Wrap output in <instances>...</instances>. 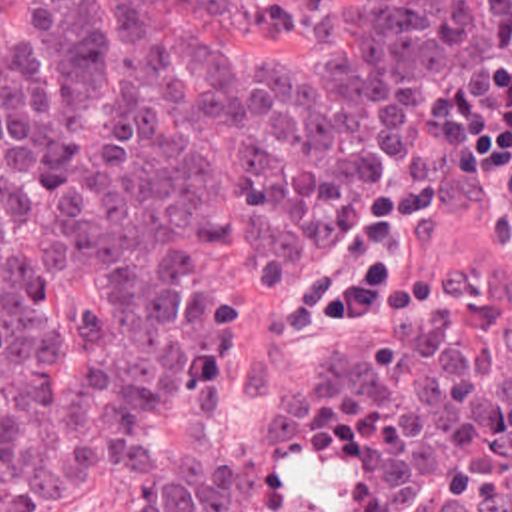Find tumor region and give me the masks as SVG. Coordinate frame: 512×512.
Returning a JSON list of instances; mask_svg holds the SVG:
<instances>
[{
	"instance_id": "1",
	"label": "tumor region",
	"mask_w": 512,
	"mask_h": 512,
	"mask_svg": "<svg viewBox=\"0 0 512 512\" xmlns=\"http://www.w3.org/2000/svg\"><path fill=\"white\" fill-rule=\"evenodd\" d=\"M184 9L250 45L214 53ZM236 245L266 291L264 512H512V0H29L0 37V512L102 475L238 512L150 441L216 391Z\"/></svg>"
}]
</instances>
